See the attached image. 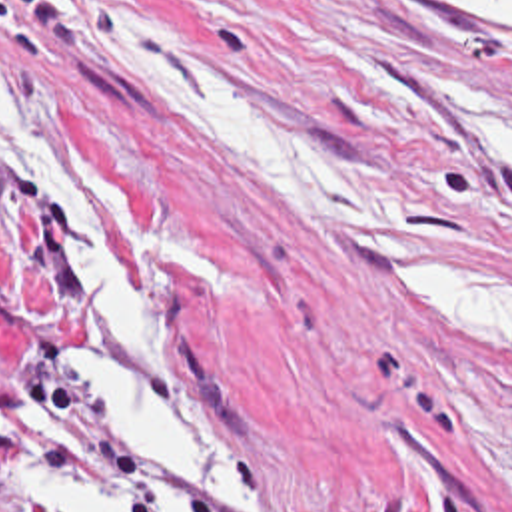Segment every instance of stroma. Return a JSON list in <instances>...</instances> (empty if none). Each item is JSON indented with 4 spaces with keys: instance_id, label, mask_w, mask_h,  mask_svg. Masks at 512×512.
<instances>
[{
    "instance_id": "1",
    "label": "stroma",
    "mask_w": 512,
    "mask_h": 512,
    "mask_svg": "<svg viewBox=\"0 0 512 512\" xmlns=\"http://www.w3.org/2000/svg\"><path fill=\"white\" fill-rule=\"evenodd\" d=\"M99 19H145L237 94L372 188L422 212L350 230L293 214L211 140L107 70ZM0 60L71 166L139 288L99 150L171 230L237 272L241 300L155 268L153 326L225 438L257 512H512V368L390 276L408 254L512 264V15L422 0H0ZM77 238L0 160V368L43 460L95 490H183L135 468L63 362L67 344L135 356L77 286ZM235 512V508H229ZM0 512H31L0 476Z\"/></svg>"
}]
</instances>
